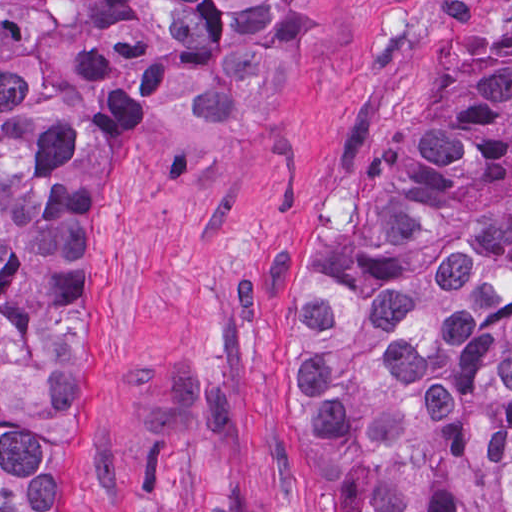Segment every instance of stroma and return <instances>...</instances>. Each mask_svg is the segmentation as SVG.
I'll return each mask as SVG.
<instances>
[{
	"instance_id": "1",
	"label": "stroma",
	"mask_w": 512,
	"mask_h": 512,
	"mask_svg": "<svg viewBox=\"0 0 512 512\" xmlns=\"http://www.w3.org/2000/svg\"><path fill=\"white\" fill-rule=\"evenodd\" d=\"M299 1L285 94L241 127L110 126L75 219L71 512H324L298 425L311 274L435 97L512 64V0Z\"/></svg>"
}]
</instances>
